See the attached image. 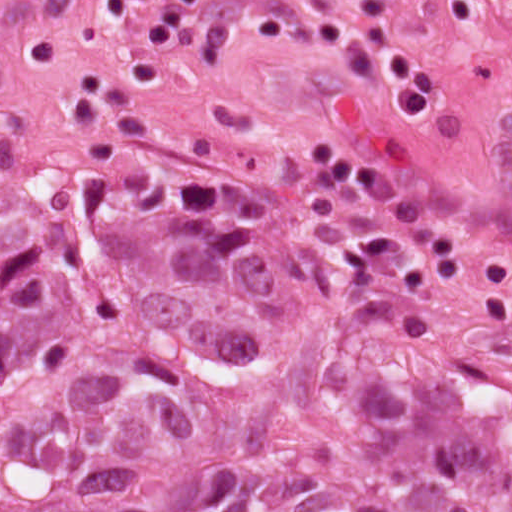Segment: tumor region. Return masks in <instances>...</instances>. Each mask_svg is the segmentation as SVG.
Listing matches in <instances>:
<instances>
[{
    "label": "tumor region",
    "mask_w": 512,
    "mask_h": 512,
    "mask_svg": "<svg viewBox=\"0 0 512 512\" xmlns=\"http://www.w3.org/2000/svg\"><path fill=\"white\" fill-rule=\"evenodd\" d=\"M1 512H512V334L369 228L50 178L1 232Z\"/></svg>",
    "instance_id": "e687c5a6"
}]
</instances>
